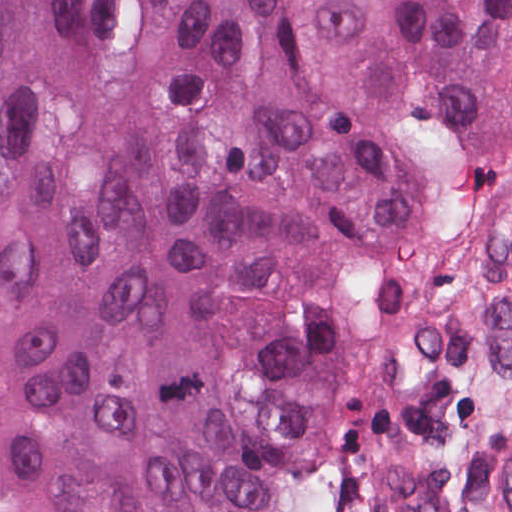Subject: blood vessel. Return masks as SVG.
Returning <instances> with one entry per match:
<instances>
[{
	"mask_svg": "<svg viewBox=\"0 0 512 512\" xmlns=\"http://www.w3.org/2000/svg\"><path fill=\"white\" fill-rule=\"evenodd\" d=\"M507 469V501L512 512V455ZM356 497L367 512H454L410 475L391 466H372L357 476Z\"/></svg>",
	"mask_w": 512,
	"mask_h": 512,
	"instance_id": "blood-vessel-1",
	"label": "blood vessel"
}]
</instances>
